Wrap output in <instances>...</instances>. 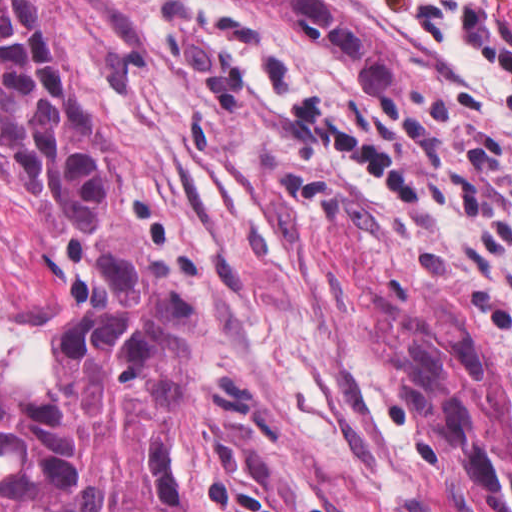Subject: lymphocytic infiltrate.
Instances as JSON below:
<instances>
[{"mask_svg":"<svg viewBox=\"0 0 512 512\" xmlns=\"http://www.w3.org/2000/svg\"><path fill=\"white\" fill-rule=\"evenodd\" d=\"M403 22L463 44L505 88L512 89V13L507 0H366Z\"/></svg>","mask_w":512,"mask_h":512,"instance_id":"obj_1","label":"lymphocytic infiltrate"}]
</instances>
